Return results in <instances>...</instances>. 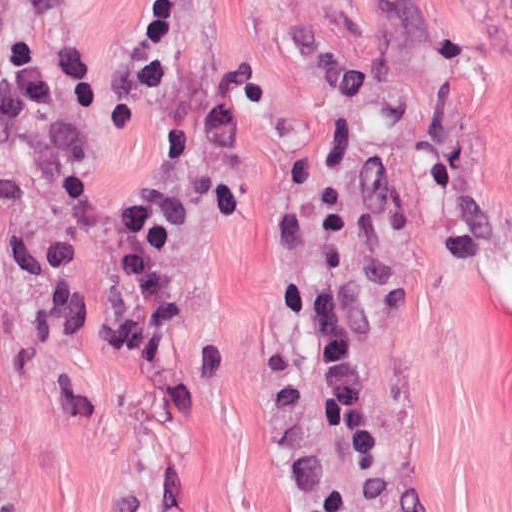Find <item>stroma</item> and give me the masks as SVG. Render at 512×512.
<instances>
[{"label": "stroma", "instance_id": "1", "mask_svg": "<svg viewBox=\"0 0 512 512\" xmlns=\"http://www.w3.org/2000/svg\"><path fill=\"white\" fill-rule=\"evenodd\" d=\"M151 0H0L94 106L0 142V512H512V0H168L175 54L257 88L226 216L178 174L163 249L173 324L153 360L90 335L132 298L74 175L129 203L167 166L192 91L137 78ZM364 71L355 110L293 29ZM343 288L379 458L312 413L319 348L287 282Z\"/></svg>", "mask_w": 512, "mask_h": 512}]
</instances>
